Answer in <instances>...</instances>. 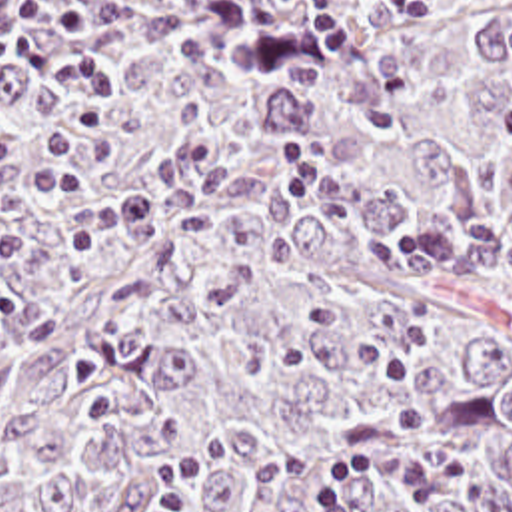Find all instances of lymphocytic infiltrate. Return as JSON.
Wrapping results in <instances>:
<instances>
[{
    "mask_svg": "<svg viewBox=\"0 0 512 512\" xmlns=\"http://www.w3.org/2000/svg\"><path fill=\"white\" fill-rule=\"evenodd\" d=\"M43 0H0V63L97 107L123 105L119 81L91 55L43 33ZM499 123L512 149V99L499 107ZM465 457H427L409 445L365 449L325 465L311 483L313 512H357L355 500L371 491H395L417 508L471 477Z\"/></svg>",
    "mask_w": 512,
    "mask_h": 512,
    "instance_id": "f902f5d3",
    "label": "lymphocytic infiltrate"
}]
</instances>
